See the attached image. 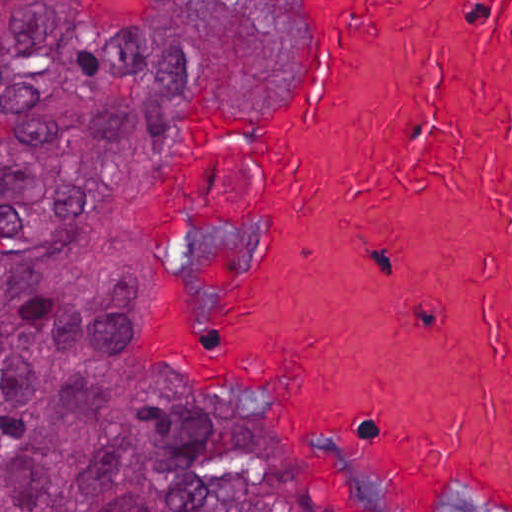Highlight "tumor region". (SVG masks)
Instances as JSON below:
<instances>
[{
	"label": "tumor region",
	"instance_id": "1",
	"mask_svg": "<svg viewBox=\"0 0 512 512\" xmlns=\"http://www.w3.org/2000/svg\"><path fill=\"white\" fill-rule=\"evenodd\" d=\"M288 0H199L120 27L63 0H0V512H301L245 394L144 375V278L233 291L215 260L130 242L153 111L183 76L264 89Z\"/></svg>",
	"mask_w": 512,
	"mask_h": 512
}]
</instances>
